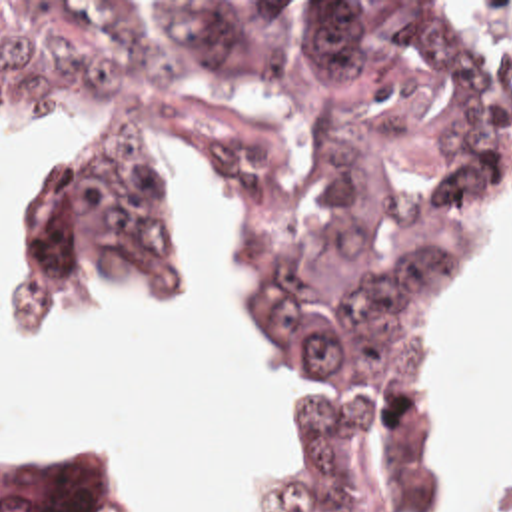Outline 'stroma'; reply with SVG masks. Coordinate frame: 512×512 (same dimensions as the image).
Returning a JSON list of instances; mask_svg holds the SVG:
<instances>
[{"instance_id":"stroma-1","label":"stroma","mask_w":512,"mask_h":512,"mask_svg":"<svg viewBox=\"0 0 512 512\" xmlns=\"http://www.w3.org/2000/svg\"><path fill=\"white\" fill-rule=\"evenodd\" d=\"M0 2H512V0H0ZM236 228H238V222H236ZM499 274L491 279V283L481 293H477L473 299H469L465 305H461L457 311L451 313L435 345V423L443 437L447 471L453 483V509L449 512H473L487 503L512 497V479L507 483H473L463 475L451 443V413H449V357H451L453 345L459 339V335L465 331V327L471 323V319L475 317L483 301L493 291Z\"/></svg>"}]
</instances>
